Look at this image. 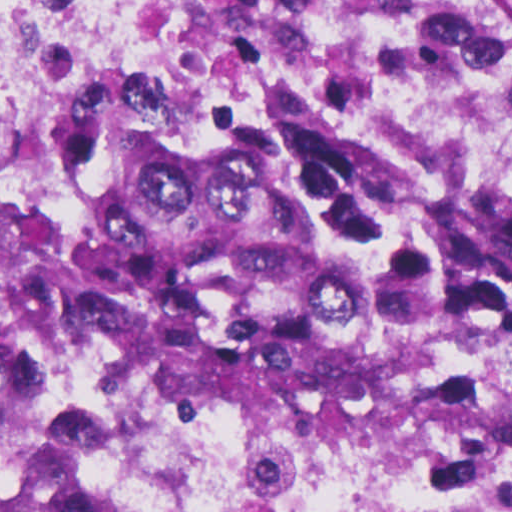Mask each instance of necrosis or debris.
<instances>
[{
    "instance_id": "obj_1",
    "label": "necrosis or debris",
    "mask_w": 512,
    "mask_h": 512,
    "mask_svg": "<svg viewBox=\"0 0 512 512\" xmlns=\"http://www.w3.org/2000/svg\"><path fill=\"white\" fill-rule=\"evenodd\" d=\"M80 57L59 18L0 43V189L67 125ZM444 428L165 375L53 330L0 359V434L85 512H512V292L482 393Z\"/></svg>"
}]
</instances>
